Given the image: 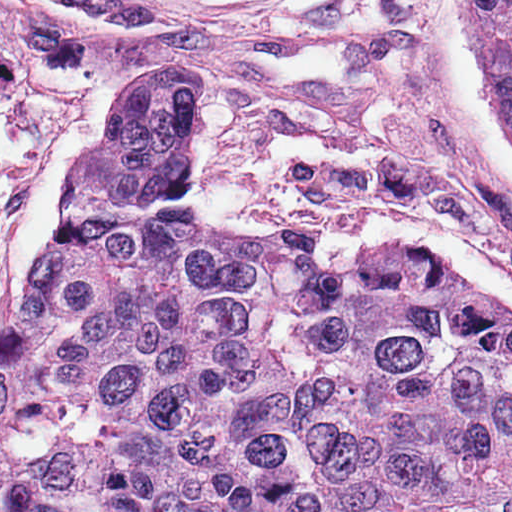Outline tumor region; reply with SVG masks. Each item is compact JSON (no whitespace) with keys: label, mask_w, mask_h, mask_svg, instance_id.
Wrapping results in <instances>:
<instances>
[{"label":"tumor region","mask_w":512,"mask_h":512,"mask_svg":"<svg viewBox=\"0 0 512 512\" xmlns=\"http://www.w3.org/2000/svg\"><path fill=\"white\" fill-rule=\"evenodd\" d=\"M464 53L512 144V0H464ZM210 95L179 63L115 86L0 333V512H512V322L210 221Z\"/></svg>","instance_id":"1"}]
</instances>
